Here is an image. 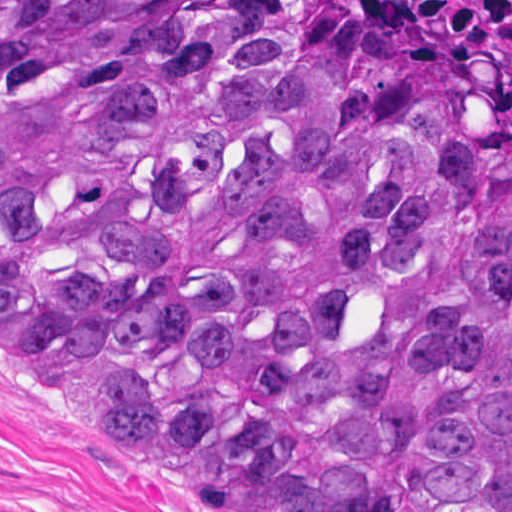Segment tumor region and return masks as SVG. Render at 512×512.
Instances as JSON below:
<instances>
[{
  "mask_svg": "<svg viewBox=\"0 0 512 512\" xmlns=\"http://www.w3.org/2000/svg\"><path fill=\"white\" fill-rule=\"evenodd\" d=\"M0 357L240 512H512V106L379 0H0Z\"/></svg>",
  "mask_w": 512,
  "mask_h": 512,
  "instance_id": "tumor-region-1",
  "label": "tumor region"
}]
</instances>
